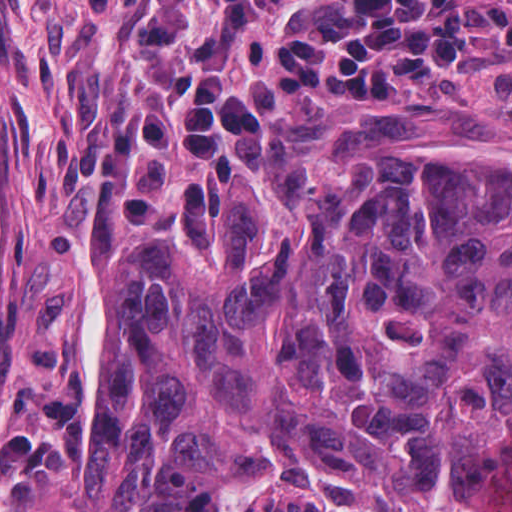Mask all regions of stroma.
<instances>
[{
	"label": "stroma",
	"instance_id": "obj_1",
	"mask_svg": "<svg viewBox=\"0 0 512 512\" xmlns=\"http://www.w3.org/2000/svg\"><path fill=\"white\" fill-rule=\"evenodd\" d=\"M84 0H0V509L9 501L10 438L38 433L44 398L77 402L67 467L39 473L12 512H69L108 338L112 263L120 245L168 214L182 184L237 187L292 142L403 147L463 139L512 150V41L492 34L452 61L424 99L388 104L358 92L282 90L236 162L169 155L157 206L120 220L72 164L73 146L119 105L115 19Z\"/></svg>",
	"mask_w": 512,
	"mask_h": 512
}]
</instances>
